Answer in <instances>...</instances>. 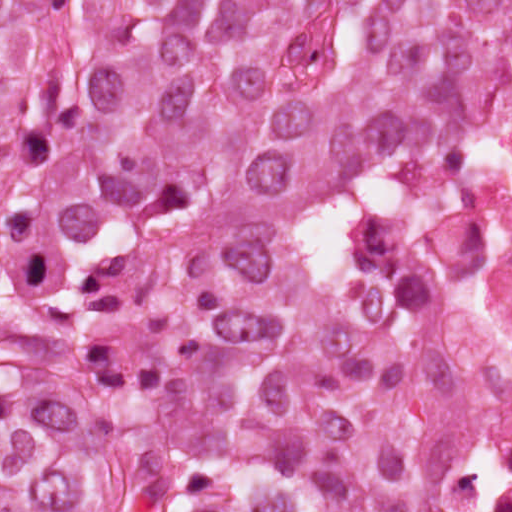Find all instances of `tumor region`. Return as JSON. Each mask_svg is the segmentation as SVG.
<instances>
[{
	"mask_svg": "<svg viewBox=\"0 0 512 512\" xmlns=\"http://www.w3.org/2000/svg\"><path fill=\"white\" fill-rule=\"evenodd\" d=\"M512 0H0V512H421L484 366L348 276Z\"/></svg>",
	"mask_w": 512,
	"mask_h": 512,
	"instance_id": "obj_1",
	"label": "tumor region"
}]
</instances>
